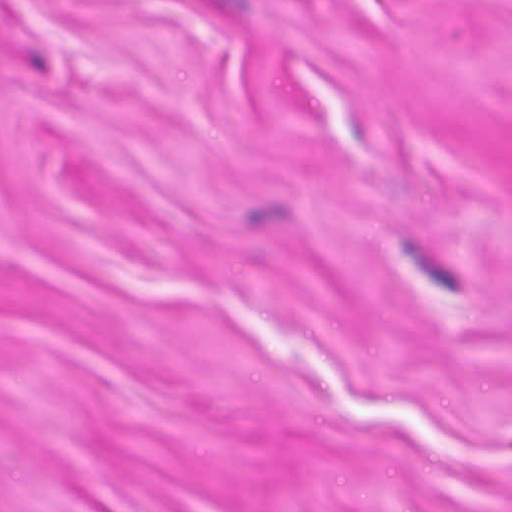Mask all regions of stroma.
<instances>
[{
  "instance_id": "stroma-1",
  "label": "stroma",
  "mask_w": 512,
  "mask_h": 512,
  "mask_svg": "<svg viewBox=\"0 0 512 512\" xmlns=\"http://www.w3.org/2000/svg\"><path fill=\"white\" fill-rule=\"evenodd\" d=\"M0 512H512V0H0Z\"/></svg>"
}]
</instances>
